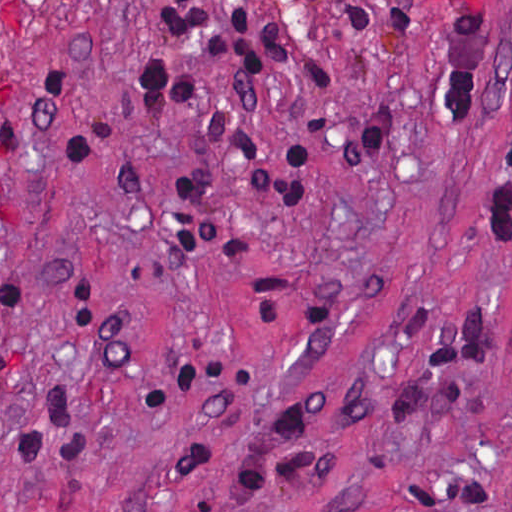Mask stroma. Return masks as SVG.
<instances>
[{
    "label": "stroma",
    "instance_id": "obj_1",
    "mask_svg": "<svg viewBox=\"0 0 512 512\" xmlns=\"http://www.w3.org/2000/svg\"><path fill=\"white\" fill-rule=\"evenodd\" d=\"M0 512H512V0H0Z\"/></svg>",
    "mask_w": 512,
    "mask_h": 512
}]
</instances>
